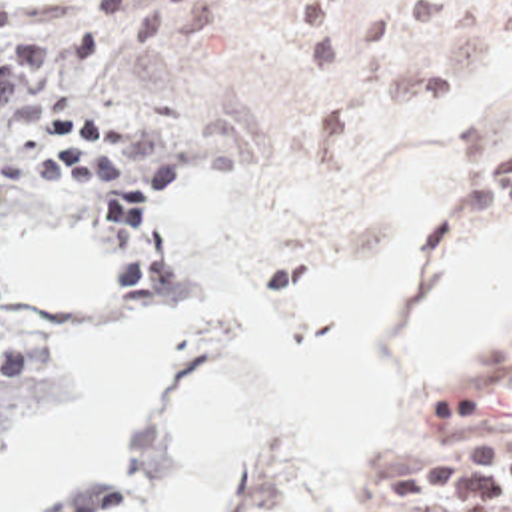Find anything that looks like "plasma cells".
<instances>
[{
	"label": "plasma cells",
	"instance_id": "plasma-cells-1",
	"mask_svg": "<svg viewBox=\"0 0 512 512\" xmlns=\"http://www.w3.org/2000/svg\"><path fill=\"white\" fill-rule=\"evenodd\" d=\"M457 200L461 210H511L512 150L467 172ZM431 424L453 450L447 460L389 476L371 494L385 506L447 502L459 512H512V366L445 400Z\"/></svg>",
	"mask_w": 512,
	"mask_h": 512
}]
</instances>
